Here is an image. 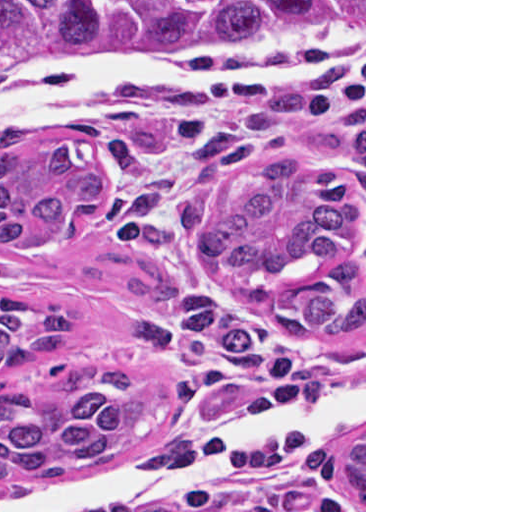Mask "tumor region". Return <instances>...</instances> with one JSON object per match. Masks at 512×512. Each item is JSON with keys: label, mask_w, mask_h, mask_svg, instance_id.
Wrapping results in <instances>:
<instances>
[{"label": "tumor region", "mask_w": 512, "mask_h": 512, "mask_svg": "<svg viewBox=\"0 0 512 512\" xmlns=\"http://www.w3.org/2000/svg\"><path fill=\"white\" fill-rule=\"evenodd\" d=\"M364 30V0H0V56L103 55L146 46L251 48ZM105 175L79 140L41 147L0 133V252L43 248ZM197 267L288 334L364 325V196L336 164L286 154L239 172L201 227ZM82 318L0 290V377L60 353ZM170 414V392L115 369L48 365L0 387V485L39 483L126 450ZM364 509V436L347 451Z\"/></svg>", "instance_id": "tumor-region-1"}]
</instances>
